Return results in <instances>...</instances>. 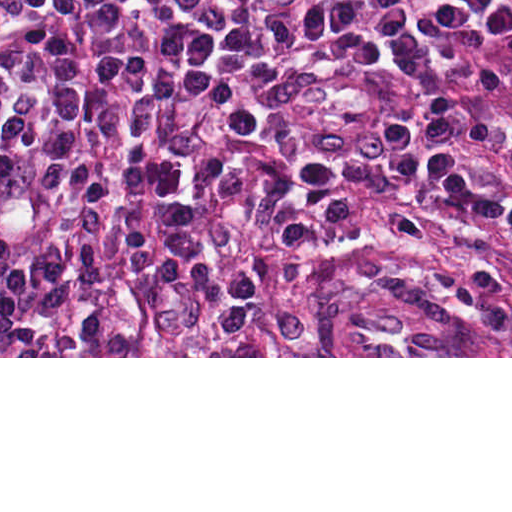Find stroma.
<instances>
[{
	"label": "stroma",
	"instance_id": "stroma-1",
	"mask_svg": "<svg viewBox=\"0 0 512 512\" xmlns=\"http://www.w3.org/2000/svg\"><path fill=\"white\" fill-rule=\"evenodd\" d=\"M257 356L512 358V233L426 190H322L284 214L251 283Z\"/></svg>",
	"mask_w": 512,
	"mask_h": 512
}]
</instances>
